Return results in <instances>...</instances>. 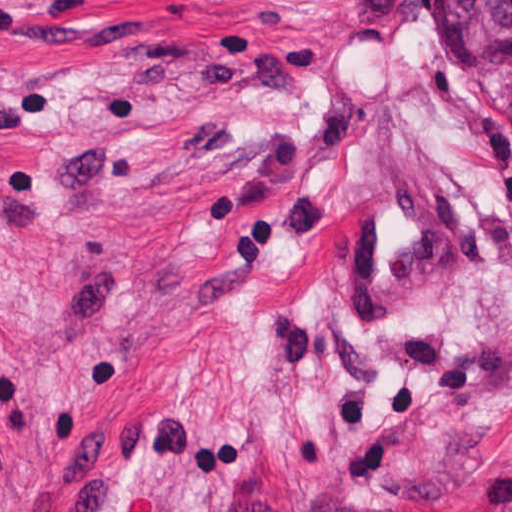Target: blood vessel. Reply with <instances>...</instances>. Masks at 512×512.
I'll use <instances>...</instances> for the list:
<instances>
[{
	"instance_id": "blood-vessel-1",
	"label": "blood vessel",
	"mask_w": 512,
	"mask_h": 512,
	"mask_svg": "<svg viewBox=\"0 0 512 512\" xmlns=\"http://www.w3.org/2000/svg\"><path fill=\"white\" fill-rule=\"evenodd\" d=\"M446 205L430 179L392 175L361 205L346 248L350 328H389L439 279Z\"/></svg>"
}]
</instances>
